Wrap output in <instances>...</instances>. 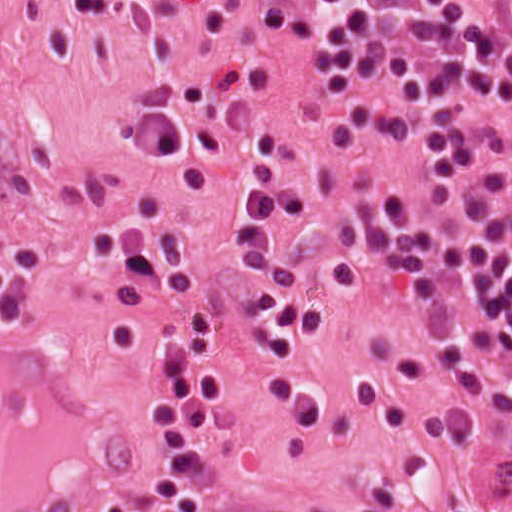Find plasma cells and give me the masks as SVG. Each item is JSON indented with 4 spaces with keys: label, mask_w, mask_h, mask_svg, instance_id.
<instances>
[{
    "label": "plasma cells",
    "mask_w": 512,
    "mask_h": 512,
    "mask_svg": "<svg viewBox=\"0 0 512 512\" xmlns=\"http://www.w3.org/2000/svg\"><path fill=\"white\" fill-rule=\"evenodd\" d=\"M135 0H63L109 19ZM475 12L458 0H312L306 33L341 116L369 145L415 161L417 194L392 193L384 286L425 332L441 384L477 442L512 438V0ZM231 246L258 271L253 328L261 384L308 443L324 416L304 385V343L324 315L306 267L281 254L271 177L229 190ZM128 279L179 308L181 343L148 395L157 494L178 512H208L214 463L208 419L223 394L219 322L178 238L143 239ZM358 512H394L385 487Z\"/></svg>",
    "instance_id": "1"
}]
</instances>
